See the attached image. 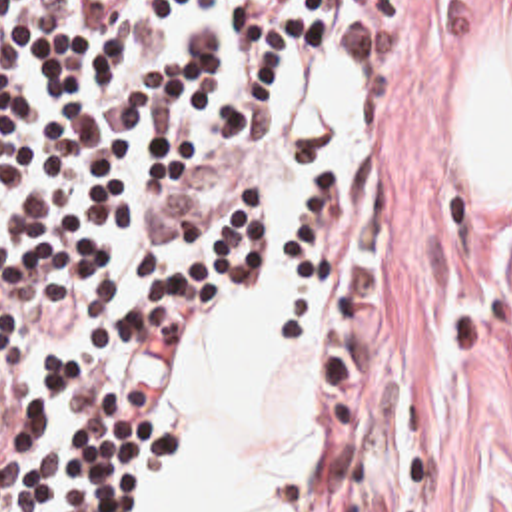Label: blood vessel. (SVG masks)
Listing matches in <instances>:
<instances>
[{
	"label": "blood vessel",
	"mask_w": 512,
	"mask_h": 512,
	"mask_svg": "<svg viewBox=\"0 0 512 512\" xmlns=\"http://www.w3.org/2000/svg\"><path fill=\"white\" fill-rule=\"evenodd\" d=\"M242 201V167L208 147L176 165L144 233L156 243H202Z\"/></svg>",
	"instance_id": "blood-vessel-1"
}]
</instances>
